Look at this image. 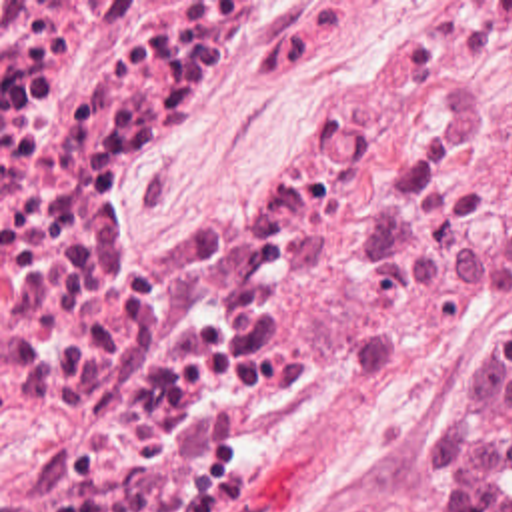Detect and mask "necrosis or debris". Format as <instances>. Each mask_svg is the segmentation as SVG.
Returning a JSON list of instances; mask_svg holds the SVG:
<instances>
[{
  "instance_id": "necrosis-or-debris-1",
  "label": "necrosis or debris",
  "mask_w": 512,
  "mask_h": 512,
  "mask_svg": "<svg viewBox=\"0 0 512 512\" xmlns=\"http://www.w3.org/2000/svg\"><path fill=\"white\" fill-rule=\"evenodd\" d=\"M310 0H0V512H198L292 366L302 256L418 334L512 310V0L392 26L250 198L162 212L138 156Z\"/></svg>"
}]
</instances>
